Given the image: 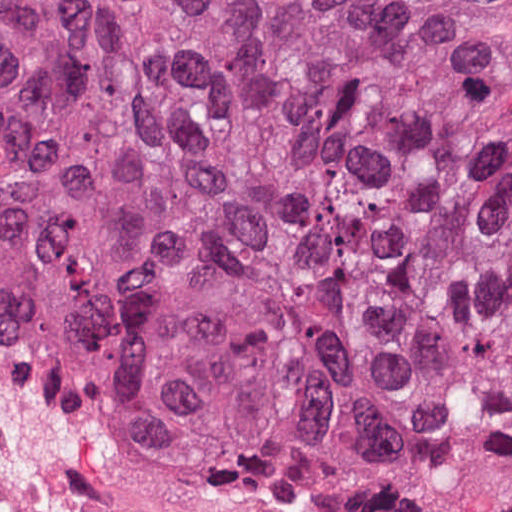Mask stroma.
<instances>
[{
    "mask_svg": "<svg viewBox=\"0 0 512 512\" xmlns=\"http://www.w3.org/2000/svg\"><path fill=\"white\" fill-rule=\"evenodd\" d=\"M512 3V0H505ZM512 151V74L503 156ZM512 509V425L446 416L349 504L229 502L0 338V512H480Z\"/></svg>",
    "mask_w": 512,
    "mask_h": 512,
    "instance_id": "obj_1",
    "label": "stroma"
}]
</instances>
